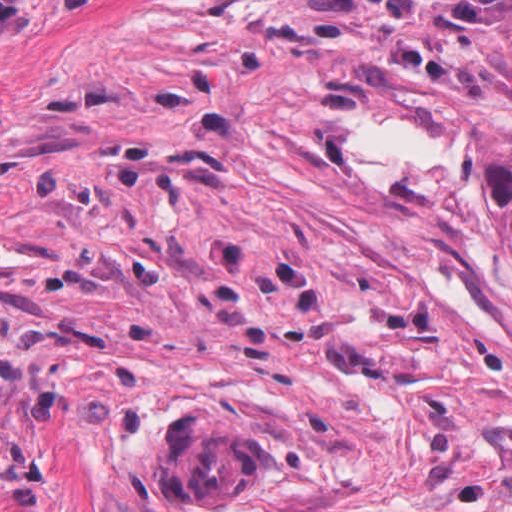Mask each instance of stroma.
<instances>
[{
  "instance_id": "stroma-1",
  "label": "stroma",
  "mask_w": 512,
  "mask_h": 512,
  "mask_svg": "<svg viewBox=\"0 0 512 512\" xmlns=\"http://www.w3.org/2000/svg\"><path fill=\"white\" fill-rule=\"evenodd\" d=\"M257 427L236 506L171 419ZM0 512H512V399L283 1L0 162Z\"/></svg>"
}]
</instances>
